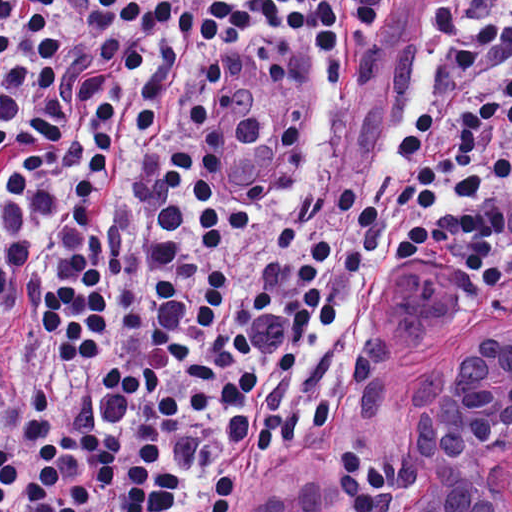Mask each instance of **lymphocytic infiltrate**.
Returning a JSON list of instances; mask_svg holds the SVG:
<instances>
[{
  "label": "lymphocytic infiltrate",
  "mask_w": 512,
  "mask_h": 512,
  "mask_svg": "<svg viewBox=\"0 0 512 512\" xmlns=\"http://www.w3.org/2000/svg\"><path fill=\"white\" fill-rule=\"evenodd\" d=\"M411 0H0V512H230L334 415L311 388L356 295L434 250L512 283V0H436L327 119L163 88L150 29L218 66L302 36L347 81ZM149 73V74H148Z\"/></svg>",
  "instance_id": "f902f5d3"
}]
</instances>
